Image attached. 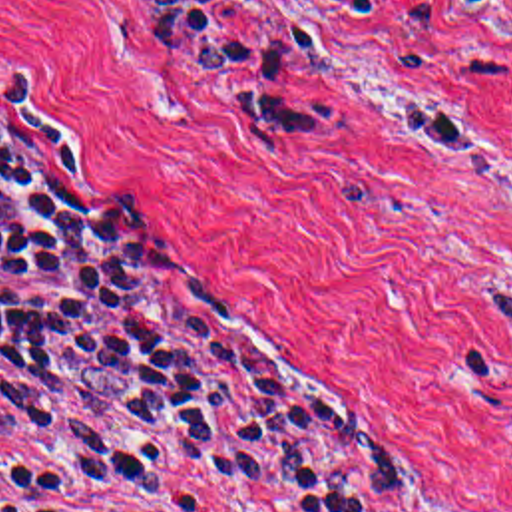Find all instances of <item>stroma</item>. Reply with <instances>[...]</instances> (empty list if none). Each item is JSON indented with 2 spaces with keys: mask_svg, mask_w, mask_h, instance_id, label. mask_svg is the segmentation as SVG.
Here are the masks:
<instances>
[{
  "mask_svg": "<svg viewBox=\"0 0 512 512\" xmlns=\"http://www.w3.org/2000/svg\"><path fill=\"white\" fill-rule=\"evenodd\" d=\"M394 27L330 0H218L346 113L324 149L202 95L125 0H0V119L61 147L133 216L206 346L410 457L382 512H512V0H396ZM334 31L312 67L294 7ZM63 447L0 413V457ZM161 512H272L202 475Z\"/></svg>",
  "mask_w": 512,
  "mask_h": 512,
  "instance_id": "stroma-1",
  "label": "stroma"
}]
</instances>
